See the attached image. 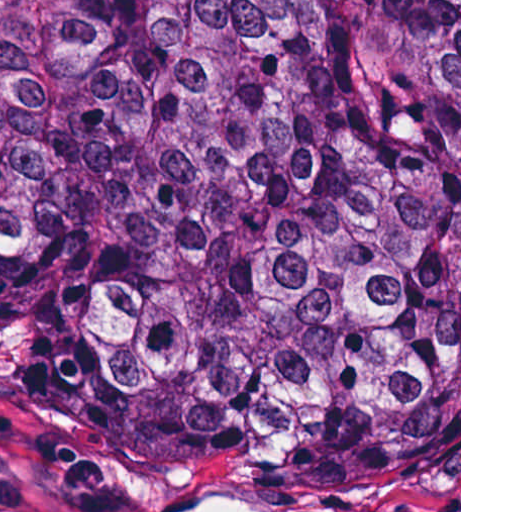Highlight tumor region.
I'll return each mask as SVG.
<instances>
[{"label":"tumor region","instance_id":"e687c5a6","mask_svg":"<svg viewBox=\"0 0 512 512\" xmlns=\"http://www.w3.org/2000/svg\"><path fill=\"white\" fill-rule=\"evenodd\" d=\"M0 249L90 414L401 512L459 455V0H0Z\"/></svg>","mask_w":512,"mask_h":512}]
</instances>
